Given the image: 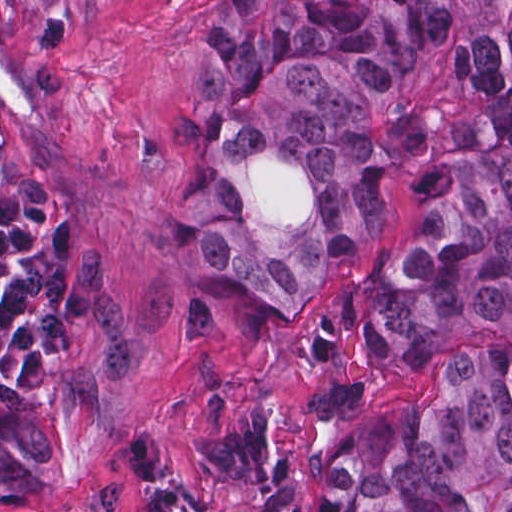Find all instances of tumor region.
Returning a JSON list of instances; mask_svg holds the SVG:
<instances>
[{
	"instance_id": "1",
	"label": "tumor region",
	"mask_w": 512,
	"mask_h": 512,
	"mask_svg": "<svg viewBox=\"0 0 512 512\" xmlns=\"http://www.w3.org/2000/svg\"><path fill=\"white\" fill-rule=\"evenodd\" d=\"M216 42L181 101L177 131L207 159L206 254L284 303L324 270L354 268L384 221V159L371 99L401 61L458 28V83L417 204L408 253L390 256L334 344L403 359L430 338L512 334L510 0H214ZM306 162L317 210L266 226L249 190L273 148ZM127 405L125 333L99 256L74 214L28 180L0 137V502L50 488V418L105 422ZM326 512H512V355L463 356L423 394L354 423L317 465ZM130 512H189L150 489Z\"/></svg>"
}]
</instances>
